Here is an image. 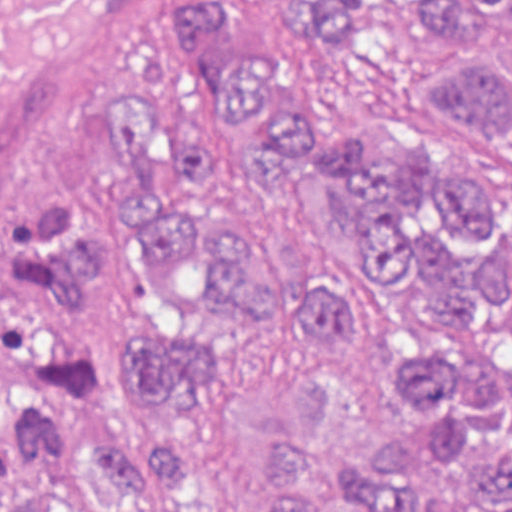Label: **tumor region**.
Masks as SVG:
<instances>
[{
	"label": "tumor region",
	"instance_id": "obj_1",
	"mask_svg": "<svg viewBox=\"0 0 512 512\" xmlns=\"http://www.w3.org/2000/svg\"><path fill=\"white\" fill-rule=\"evenodd\" d=\"M298 19V47L244 53L229 0H172L170 37L199 93L182 114L154 86H126L109 117L136 204L109 214L88 193L31 203L9 255L54 327L82 311L120 249L149 243L187 326L133 347L120 410L183 421L260 322L319 321L348 343L378 321L353 291L293 275L251 201L217 170L244 160L324 233L373 256L432 315L388 348L382 377L409 433L352 459L339 371L312 359L293 410L265 426L255 512H512V220L499 192L435 139L387 155L369 131L318 142L293 81L306 51L356 45L381 16L446 42L412 80L512 152V0H267ZM12 454L88 485L102 512H192L189 437L90 421L66 394L23 390ZM18 512H76L23 496Z\"/></svg>",
	"mask_w": 512,
	"mask_h": 512
}]
</instances>
